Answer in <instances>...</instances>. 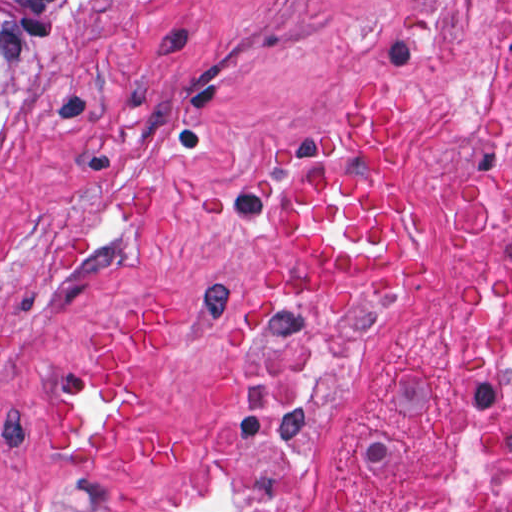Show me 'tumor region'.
I'll return each mask as SVG.
<instances>
[{"label": "tumor region", "mask_w": 512, "mask_h": 512, "mask_svg": "<svg viewBox=\"0 0 512 512\" xmlns=\"http://www.w3.org/2000/svg\"><path fill=\"white\" fill-rule=\"evenodd\" d=\"M75 1H0V114Z\"/></svg>", "instance_id": "tumor-region-1"}]
</instances>
